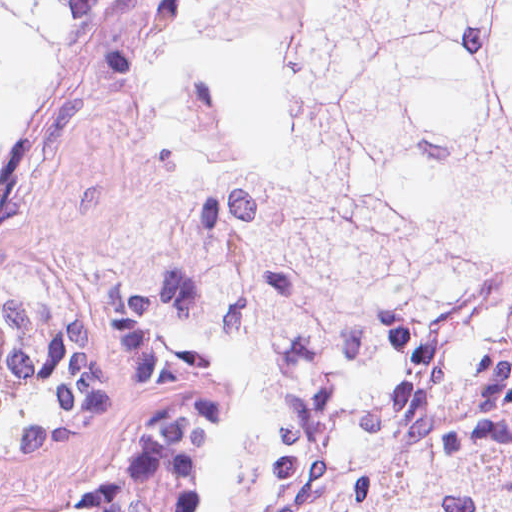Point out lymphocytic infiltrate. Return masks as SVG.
<instances>
[{
  "label": "lymphocytic infiltrate",
  "instance_id": "f902f5d3",
  "mask_svg": "<svg viewBox=\"0 0 512 512\" xmlns=\"http://www.w3.org/2000/svg\"><path fill=\"white\" fill-rule=\"evenodd\" d=\"M238 403L222 382L213 402V498L216 512H257L264 464L236 439Z\"/></svg>",
  "mask_w": 512,
  "mask_h": 512
}]
</instances>
